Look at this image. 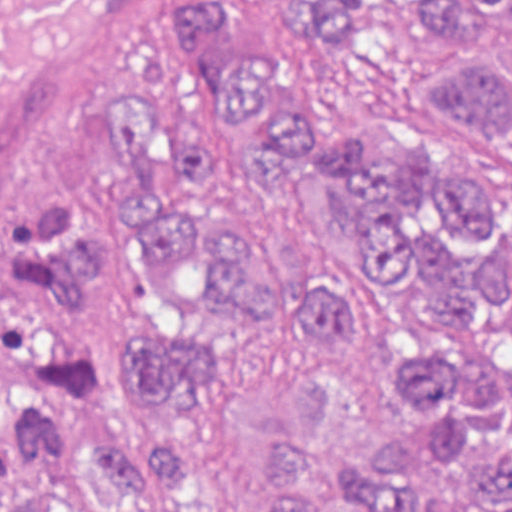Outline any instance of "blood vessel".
Listing matches in <instances>:
<instances>
[{"label": "blood vessel", "mask_w": 512, "mask_h": 512, "mask_svg": "<svg viewBox=\"0 0 512 512\" xmlns=\"http://www.w3.org/2000/svg\"><path fill=\"white\" fill-rule=\"evenodd\" d=\"M152 0H0V171L70 75Z\"/></svg>", "instance_id": "8fb6f2fc"}]
</instances>
